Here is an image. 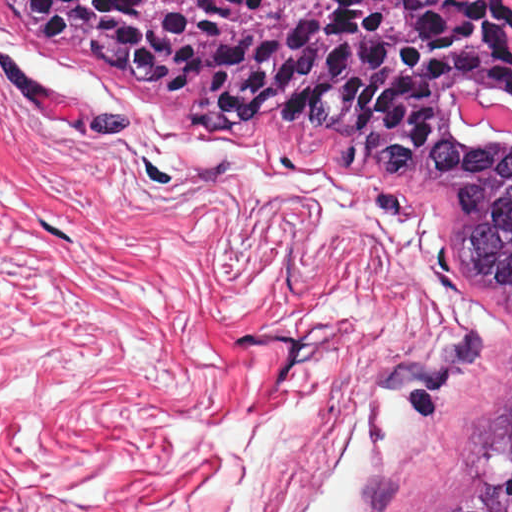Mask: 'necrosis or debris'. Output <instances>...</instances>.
<instances>
[{
	"mask_svg": "<svg viewBox=\"0 0 512 512\" xmlns=\"http://www.w3.org/2000/svg\"><path fill=\"white\" fill-rule=\"evenodd\" d=\"M460 110L466 123L476 127L488 124L512 139V105L492 104L470 95L465 97Z\"/></svg>",
	"mask_w": 512,
	"mask_h": 512,
	"instance_id": "necrosis-or-debris-1",
	"label": "necrosis or debris"
}]
</instances>
